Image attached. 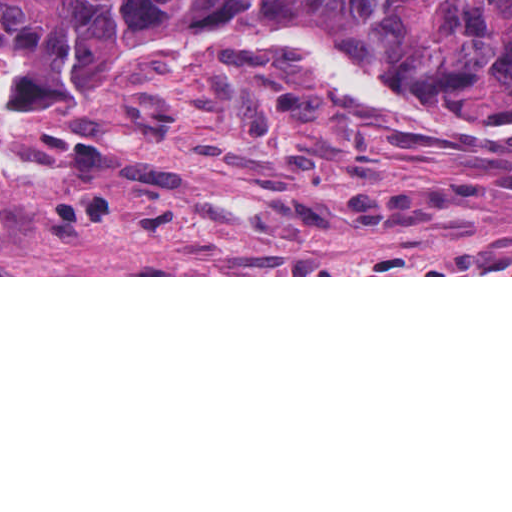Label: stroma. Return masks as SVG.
<instances>
[{
    "label": "stroma",
    "mask_w": 512,
    "mask_h": 512,
    "mask_svg": "<svg viewBox=\"0 0 512 512\" xmlns=\"http://www.w3.org/2000/svg\"><path fill=\"white\" fill-rule=\"evenodd\" d=\"M9 69L0 44V121ZM512 131L193 24L81 113L0 124V277H512Z\"/></svg>",
    "instance_id": "35a3bbf8"
}]
</instances>
